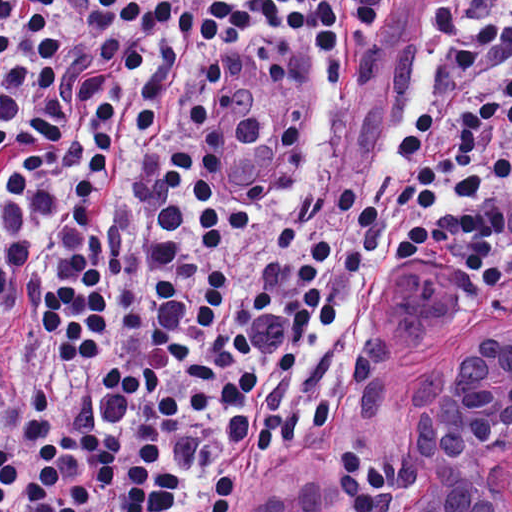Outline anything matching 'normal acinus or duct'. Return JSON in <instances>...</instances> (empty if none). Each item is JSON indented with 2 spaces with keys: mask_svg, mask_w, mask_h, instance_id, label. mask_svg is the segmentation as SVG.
<instances>
[{
  "mask_svg": "<svg viewBox=\"0 0 512 512\" xmlns=\"http://www.w3.org/2000/svg\"><path fill=\"white\" fill-rule=\"evenodd\" d=\"M399 270L373 356L411 396V468L393 512H512V313L444 274Z\"/></svg>",
  "mask_w": 512,
  "mask_h": 512,
  "instance_id": "30e58d81",
  "label": "normal acinus or duct"
}]
</instances>
